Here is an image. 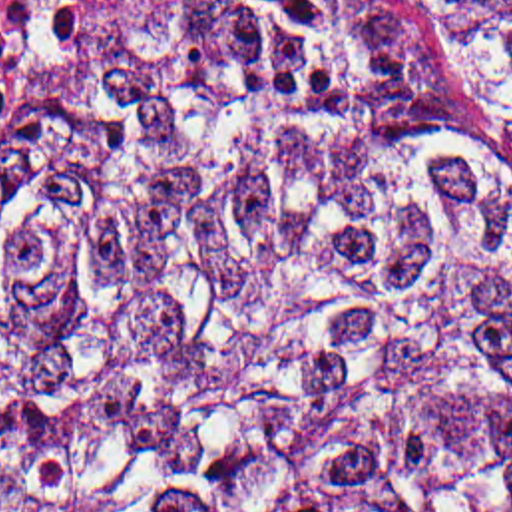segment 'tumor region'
<instances>
[{"mask_svg":"<svg viewBox=\"0 0 512 512\" xmlns=\"http://www.w3.org/2000/svg\"><path fill=\"white\" fill-rule=\"evenodd\" d=\"M0 512H512V0H125L0 117Z\"/></svg>","mask_w":512,"mask_h":512,"instance_id":"obj_1","label":"tumor region"}]
</instances>
